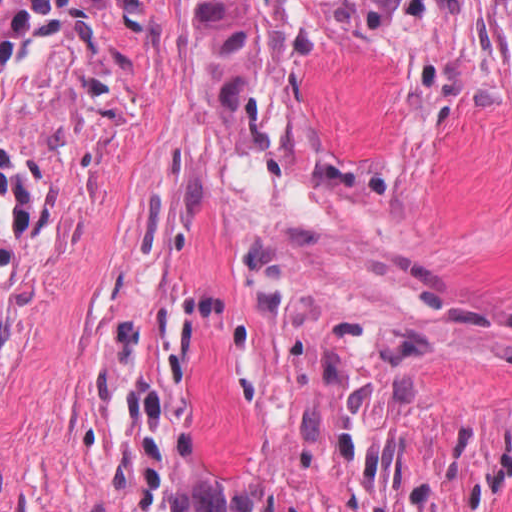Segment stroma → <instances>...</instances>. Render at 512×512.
<instances>
[{
	"mask_svg": "<svg viewBox=\"0 0 512 512\" xmlns=\"http://www.w3.org/2000/svg\"><path fill=\"white\" fill-rule=\"evenodd\" d=\"M0 512H144L1 264Z\"/></svg>",
	"mask_w": 512,
	"mask_h": 512,
	"instance_id": "1",
	"label": "stroma"
}]
</instances>
